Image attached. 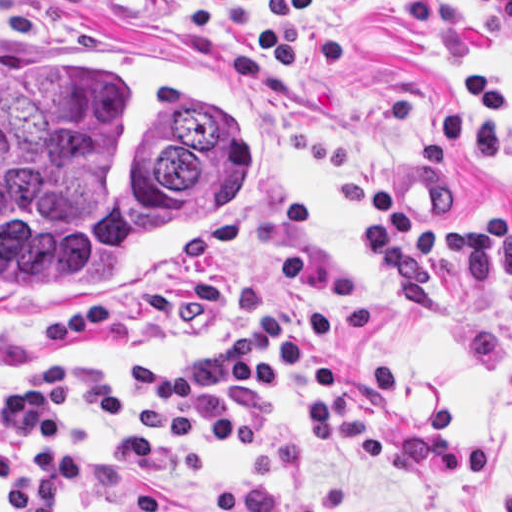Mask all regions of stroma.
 I'll return each instance as SVG.
<instances>
[{
	"mask_svg": "<svg viewBox=\"0 0 512 512\" xmlns=\"http://www.w3.org/2000/svg\"><path fill=\"white\" fill-rule=\"evenodd\" d=\"M105 33L193 49L237 64L247 32L203 34L189 1L72 0ZM430 46L375 0H332L319 19L348 30V70L308 53L310 87L255 83L263 149L251 219L233 262L97 314L0 324V389L33 362L86 360L119 378L130 405L114 421L68 418L102 440H133L136 366L180 364L235 337L242 285L264 283L292 329L345 360L347 388L383 425L388 460L365 464L348 441L320 457L297 386L249 403L206 399L204 420H260L252 451L203 447V478L155 487L184 512H210L224 488L270 483L323 512H512V278L461 284L435 259L433 311L401 307L362 252L376 197L434 215H512V34L480 0H430ZM94 471L95 452L66 449ZM141 482L148 484L144 480ZM0 512H19L0 487ZM56 512H99L61 499Z\"/></svg>",
	"mask_w": 512,
	"mask_h": 512,
	"instance_id": "35a3bbf8",
	"label": "stroma"
}]
</instances>
